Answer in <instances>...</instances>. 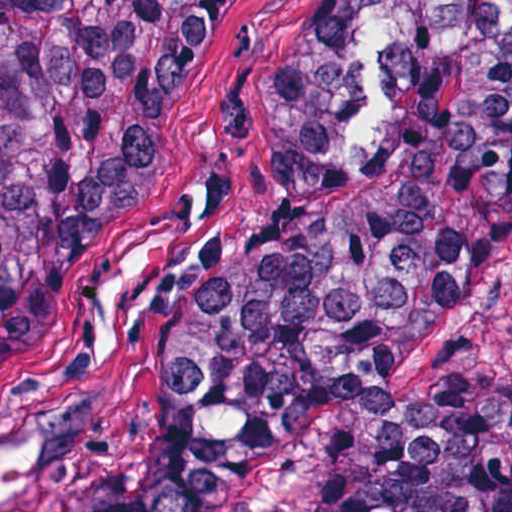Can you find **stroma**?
<instances>
[{"instance_id":"stroma-1","label":"stroma","mask_w":512,"mask_h":512,"mask_svg":"<svg viewBox=\"0 0 512 512\" xmlns=\"http://www.w3.org/2000/svg\"><path fill=\"white\" fill-rule=\"evenodd\" d=\"M356 1L221 0L68 269L0 350V496L35 469H88L157 395L271 224L274 107ZM448 375L512 379V244L414 337L391 413L323 418L211 512H312L324 473Z\"/></svg>"}]
</instances>
